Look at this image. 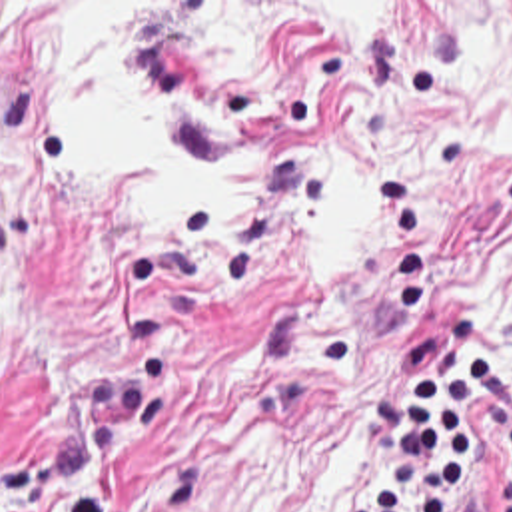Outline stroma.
Returning a JSON list of instances; mask_svg holds the SVG:
<instances>
[{
	"instance_id": "35a3bbf8",
	"label": "stroma",
	"mask_w": 512,
	"mask_h": 512,
	"mask_svg": "<svg viewBox=\"0 0 512 512\" xmlns=\"http://www.w3.org/2000/svg\"><path fill=\"white\" fill-rule=\"evenodd\" d=\"M151 2L125 48L153 128L203 162L275 156L315 120L381 166L359 268L313 252L311 160L207 228L139 214L121 164L0 341V512H347L383 447L391 343L512 373V0H0L6 22ZM72 176L42 62L0 54V278ZM511 431L471 425L469 493L499 512Z\"/></svg>"
}]
</instances>
